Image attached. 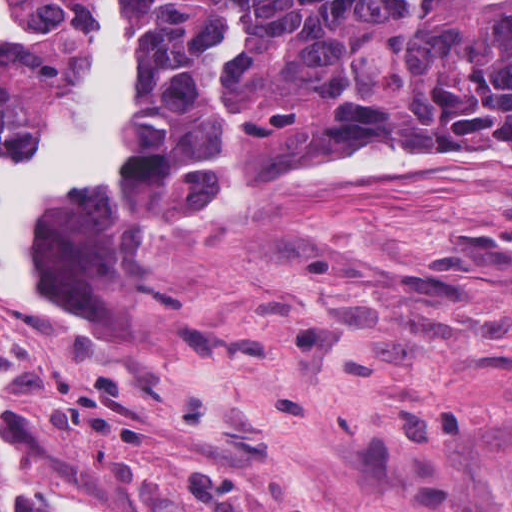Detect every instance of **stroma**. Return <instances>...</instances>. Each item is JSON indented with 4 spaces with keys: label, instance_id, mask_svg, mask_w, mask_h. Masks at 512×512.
Wrapping results in <instances>:
<instances>
[{
    "label": "stroma",
    "instance_id": "stroma-1",
    "mask_svg": "<svg viewBox=\"0 0 512 512\" xmlns=\"http://www.w3.org/2000/svg\"><path fill=\"white\" fill-rule=\"evenodd\" d=\"M151 5L123 0L135 124ZM463 143L325 138L214 213L114 200L113 172L49 210L37 270L89 322L0 295V470L98 512H512V172L282 175Z\"/></svg>",
    "mask_w": 512,
    "mask_h": 512
}]
</instances>
